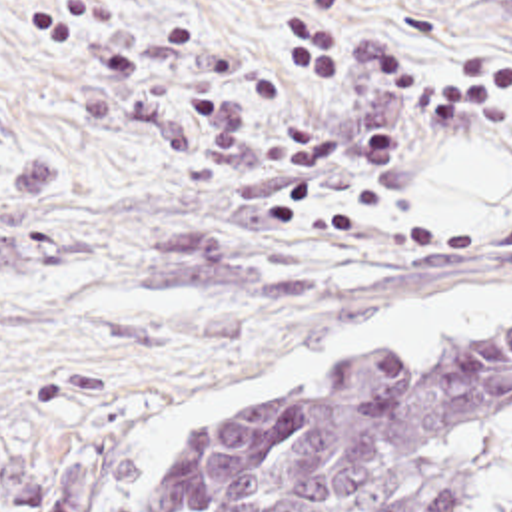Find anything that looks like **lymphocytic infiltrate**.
Instances as JSON below:
<instances>
[{
	"label": "lymphocytic infiltrate",
	"mask_w": 512,
	"mask_h": 512,
	"mask_svg": "<svg viewBox=\"0 0 512 512\" xmlns=\"http://www.w3.org/2000/svg\"><path fill=\"white\" fill-rule=\"evenodd\" d=\"M284 7L282 71L294 93L381 97L419 123H475L485 111L512 107V55H463L423 79L403 47L355 35L345 0H284Z\"/></svg>",
	"instance_id": "1"
}]
</instances>
